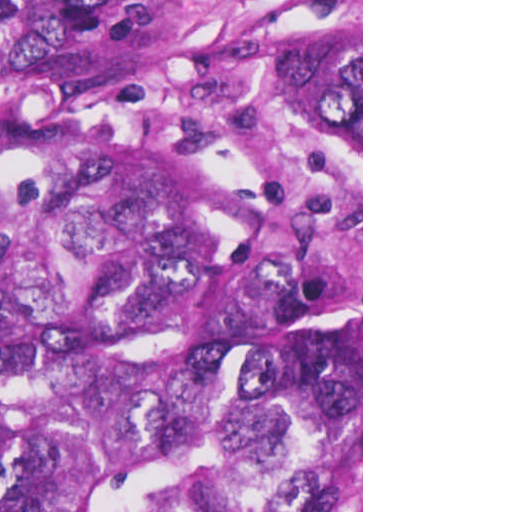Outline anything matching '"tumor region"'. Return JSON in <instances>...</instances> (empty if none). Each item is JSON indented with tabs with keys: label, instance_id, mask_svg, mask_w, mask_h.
<instances>
[{
	"label": "tumor region",
	"instance_id": "tumor-region-1",
	"mask_svg": "<svg viewBox=\"0 0 512 512\" xmlns=\"http://www.w3.org/2000/svg\"><path fill=\"white\" fill-rule=\"evenodd\" d=\"M361 425V1H0V512H327Z\"/></svg>",
	"mask_w": 512,
	"mask_h": 512
}]
</instances>
